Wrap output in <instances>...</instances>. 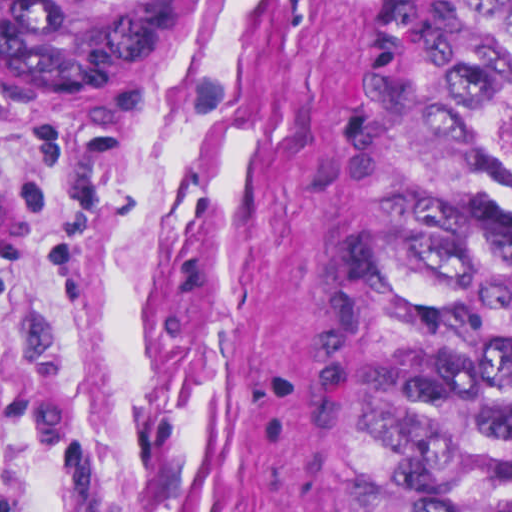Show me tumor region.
Masks as SVG:
<instances>
[{
  "mask_svg": "<svg viewBox=\"0 0 512 512\" xmlns=\"http://www.w3.org/2000/svg\"><path fill=\"white\" fill-rule=\"evenodd\" d=\"M183 0H0V101L86 120L167 72ZM410 147L369 304L379 512H512V0H405Z\"/></svg>",
  "mask_w": 512,
  "mask_h": 512,
  "instance_id": "e687c5a6",
  "label": "tumor region"
}]
</instances>
